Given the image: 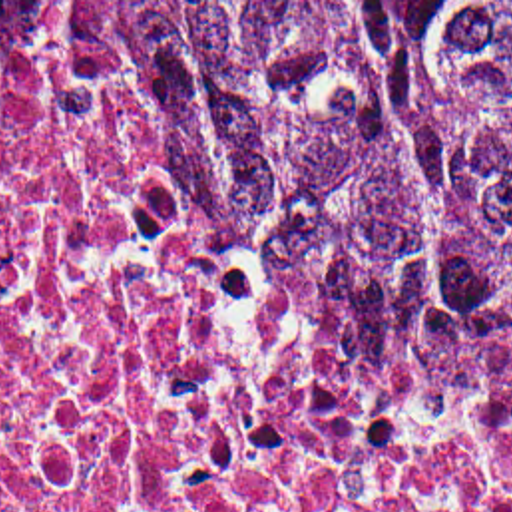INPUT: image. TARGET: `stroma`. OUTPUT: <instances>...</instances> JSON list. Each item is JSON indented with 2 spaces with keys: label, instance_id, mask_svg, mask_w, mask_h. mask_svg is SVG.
Masks as SVG:
<instances>
[{
  "label": "stroma",
  "instance_id": "35a3bbf8",
  "mask_svg": "<svg viewBox=\"0 0 512 512\" xmlns=\"http://www.w3.org/2000/svg\"><path fill=\"white\" fill-rule=\"evenodd\" d=\"M0 2H512V0H0ZM0 34H93L121 38L109 30H0Z\"/></svg>",
  "mask_w": 512,
  "mask_h": 512
}]
</instances>
